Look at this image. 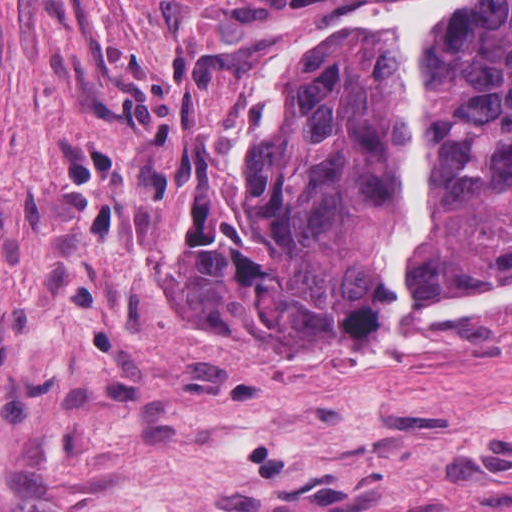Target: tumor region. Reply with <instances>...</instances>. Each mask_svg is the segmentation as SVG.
<instances>
[{
  "instance_id": "obj_1",
  "label": "tumor region",
  "mask_w": 512,
  "mask_h": 512,
  "mask_svg": "<svg viewBox=\"0 0 512 512\" xmlns=\"http://www.w3.org/2000/svg\"><path fill=\"white\" fill-rule=\"evenodd\" d=\"M417 132L432 235L421 285L454 299L512 278V0H469L436 35ZM404 180L381 35L320 41L308 102L249 139L226 206L203 228L191 297L272 368H375L391 328L383 247Z\"/></svg>"
}]
</instances>
